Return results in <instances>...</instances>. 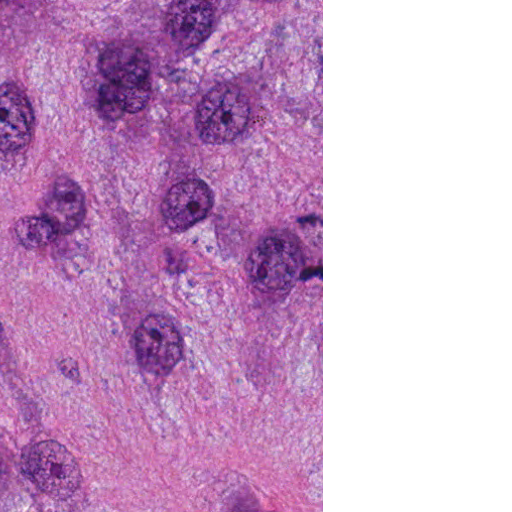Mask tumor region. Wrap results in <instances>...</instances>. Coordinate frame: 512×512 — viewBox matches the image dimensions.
Listing matches in <instances>:
<instances>
[{
    "mask_svg": "<svg viewBox=\"0 0 512 512\" xmlns=\"http://www.w3.org/2000/svg\"><path fill=\"white\" fill-rule=\"evenodd\" d=\"M0 512H161V0H0Z\"/></svg>",
    "mask_w": 512,
    "mask_h": 512,
    "instance_id": "1",
    "label": "tumor region"
}]
</instances>
